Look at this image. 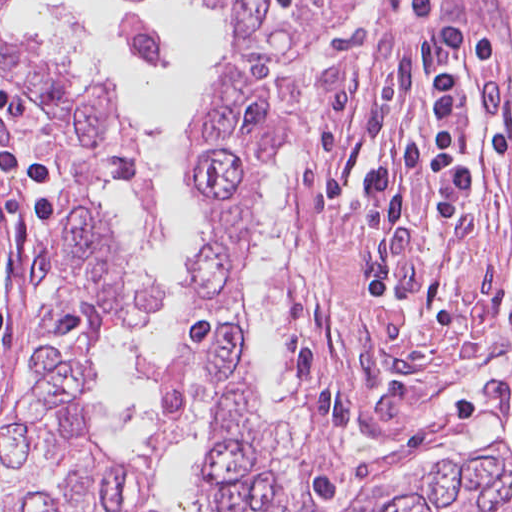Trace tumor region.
Here are the masks:
<instances>
[{"label": "tumor region", "instance_id": "tumor-region-1", "mask_svg": "<svg viewBox=\"0 0 512 512\" xmlns=\"http://www.w3.org/2000/svg\"><path fill=\"white\" fill-rule=\"evenodd\" d=\"M328 1L214 0L228 54L212 72L198 130L188 136L186 171L209 233L182 270L211 308L172 347L162 400L189 409L192 381L203 378L213 414L212 473L231 512H512V459L501 445L443 459L391 495L309 504L248 387L234 297L257 205L288 146L307 82L309 69L296 68L293 56ZM0 73L49 107L70 253L44 359L0 419V512H129L143 500L139 478L85 442L83 363L106 325L156 313L162 300L119 227L93 208L88 186L119 182L137 218L155 231L164 230L165 201L115 93L1 30Z\"/></svg>", "mask_w": 512, "mask_h": 512}]
</instances>
